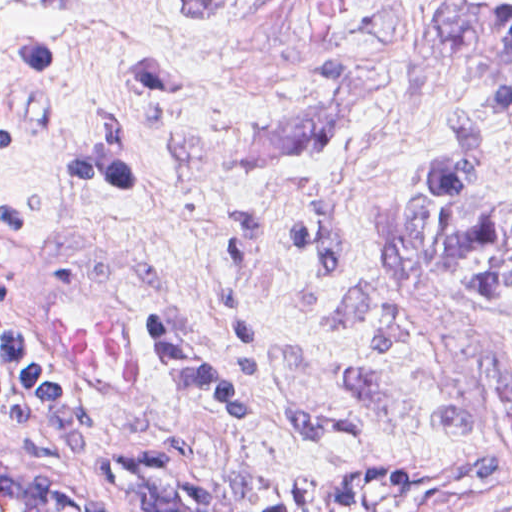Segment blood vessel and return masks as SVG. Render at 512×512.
Segmentation results:
<instances>
[{
  "label": "blood vessel",
  "instance_id": "obj_1",
  "mask_svg": "<svg viewBox=\"0 0 512 512\" xmlns=\"http://www.w3.org/2000/svg\"><path fill=\"white\" fill-rule=\"evenodd\" d=\"M40 272L30 290L34 340L86 395L119 410L150 401L136 332L113 301L72 269ZM0 512H120L97 486L0 448Z\"/></svg>",
  "mask_w": 512,
  "mask_h": 512
}]
</instances>
